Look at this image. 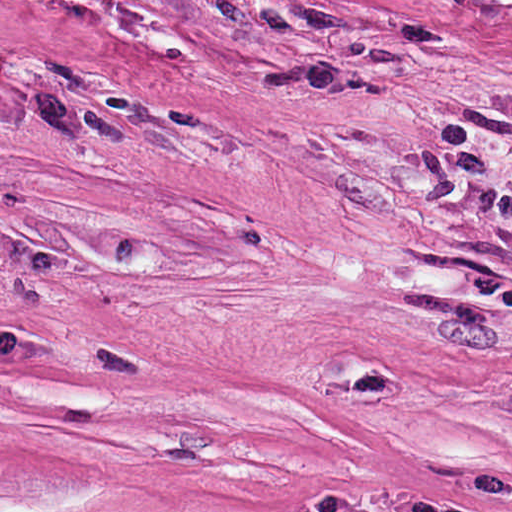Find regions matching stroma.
Returning a JSON list of instances; mask_svg holds the SVG:
<instances>
[{
  "mask_svg": "<svg viewBox=\"0 0 512 512\" xmlns=\"http://www.w3.org/2000/svg\"><path fill=\"white\" fill-rule=\"evenodd\" d=\"M0 310L512 476V0H0Z\"/></svg>",
  "mask_w": 512,
  "mask_h": 512,
  "instance_id": "35a3bbf8",
  "label": "stroma"
}]
</instances>
